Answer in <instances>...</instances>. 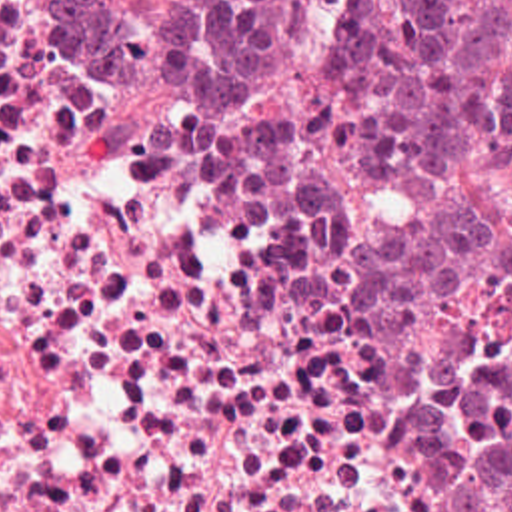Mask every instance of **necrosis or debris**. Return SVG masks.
<instances>
[{
    "label": "necrosis or debris",
    "mask_w": 512,
    "mask_h": 512,
    "mask_svg": "<svg viewBox=\"0 0 512 512\" xmlns=\"http://www.w3.org/2000/svg\"><path fill=\"white\" fill-rule=\"evenodd\" d=\"M509 345L481 293L339 305L305 125L0 0V512H453L423 418Z\"/></svg>",
    "instance_id": "4bbe7bcc"
}]
</instances>
